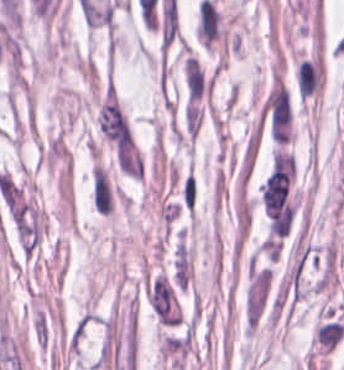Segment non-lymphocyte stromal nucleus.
Listing matches in <instances>:
<instances>
[{
  "mask_svg": "<svg viewBox=\"0 0 344 370\" xmlns=\"http://www.w3.org/2000/svg\"><path fill=\"white\" fill-rule=\"evenodd\" d=\"M91 203L94 210L102 215H109L112 210L111 192L101 165L93 164L91 169Z\"/></svg>",
  "mask_w": 344,
  "mask_h": 370,
  "instance_id": "dd21d789",
  "label": "non-lymphocyte stromal nucleus"
},
{
  "mask_svg": "<svg viewBox=\"0 0 344 370\" xmlns=\"http://www.w3.org/2000/svg\"><path fill=\"white\" fill-rule=\"evenodd\" d=\"M315 338L322 352H329L337 346L344 335V325L339 321L320 324L315 330Z\"/></svg>",
  "mask_w": 344,
  "mask_h": 370,
  "instance_id": "a72fc3eb",
  "label": "non-lymphocyte stromal nucleus"
}]
</instances>
